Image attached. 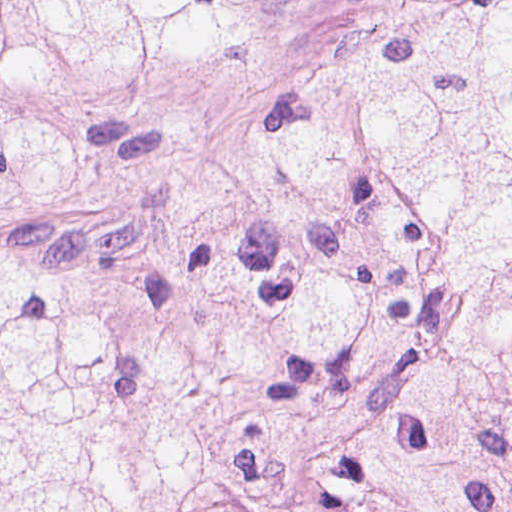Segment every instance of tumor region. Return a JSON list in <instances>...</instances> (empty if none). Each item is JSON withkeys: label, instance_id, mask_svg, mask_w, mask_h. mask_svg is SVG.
<instances>
[{"label": "tumor region", "instance_id": "tumor-region-1", "mask_svg": "<svg viewBox=\"0 0 512 512\" xmlns=\"http://www.w3.org/2000/svg\"><path fill=\"white\" fill-rule=\"evenodd\" d=\"M281 0H0L74 92ZM222 134L158 291L0 243V512H512V0H403ZM59 131L0 124V205Z\"/></svg>", "mask_w": 512, "mask_h": 512}]
</instances>
